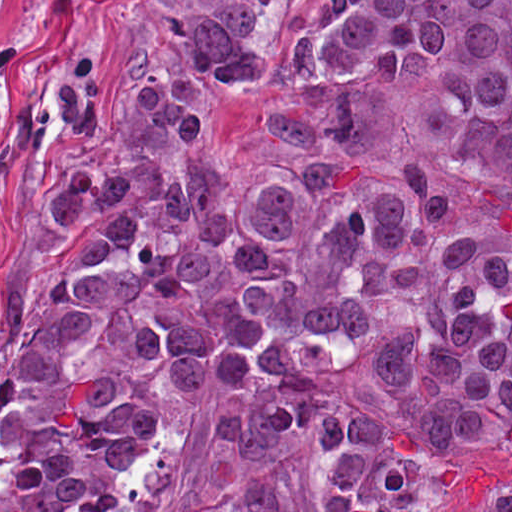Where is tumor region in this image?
Listing matches in <instances>:
<instances>
[{"label":"tumor region","instance_id":"tumor-region-1","mask_svg":"<svg viewBox=\"0 0 512 512\" xmlns=\"http://www.w3.org/2000/svg\"><path fill=\"white\" fill-rule=\"evenodd\" d=\"M200 0L124 127L50 189L74 245L0 364V512H512V0H315L242 110L286 152L222 173L217 89L262 74Z\"/></svg>","mask_w":512,"mask_h":512}]
</instances>
